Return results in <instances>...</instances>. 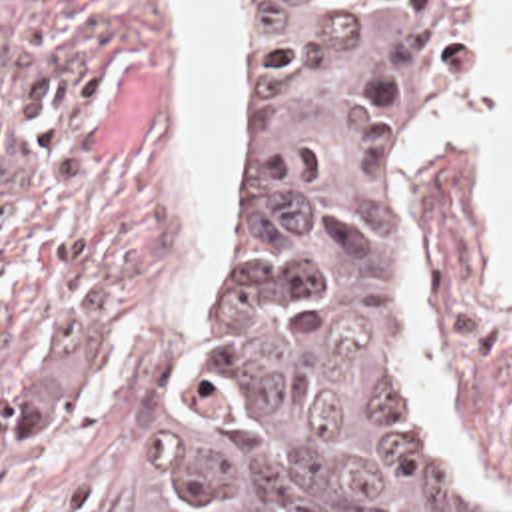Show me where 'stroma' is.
I'll use <instances>...</instances> for the list:
<instances>
[{
  "instance_id": "1",
  "label": "stroma",
  "mask_w": 512,
  "mask_h": 512,
  "mask_svg": "<svg viewBox=\"0 0 512 512\" xmlns=\"http://www.w3.org/2000/svg\"><path fill=\"white\" fill-rule=\"evenodd\" d=\"M467 0L421 77L397 163L419 358L512 512V291L485 295V213L457 147L409 149ZM233 165L209 277L162 0H0V512H142L166 434L263 233V63L233 0Z\"/></svg>"
}]
</instances>
